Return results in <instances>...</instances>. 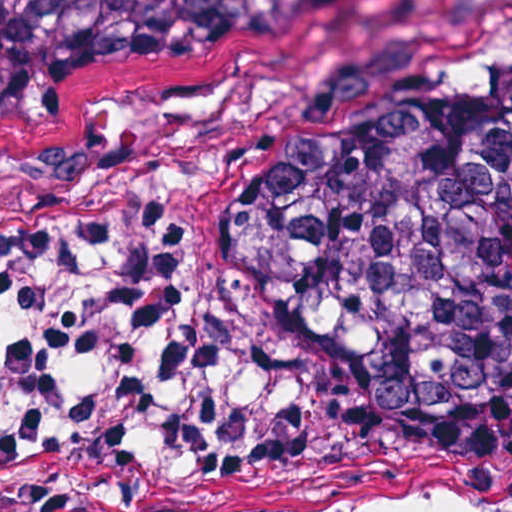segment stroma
I'll return each instance as SVG.
<instances>
[{
	"mask_svg": "<svg viewBox=\"0 0 512 512\" xmlns=\"http://www.w3.org/2000/svg\"><path fill=\"white\" fill-rule=\"evenodd\" d=\"M493 0H378L326 64L93 84L0 124V236L55 219L172 202L187 273L222 250L229 185L258 144L327 85L376 75L385 94L464 42ZM181 275V276H182ZM228 414L288 428L274 463L143 512L481 509L512 503V431L433 426L353 402L297 369L220 390Z\"/></svg>",
	"mask_w": 512,
	"mask_h": 512,
	"instance_id": "35a3bbf8",
	"label": "stroma"
}]
</instances>
